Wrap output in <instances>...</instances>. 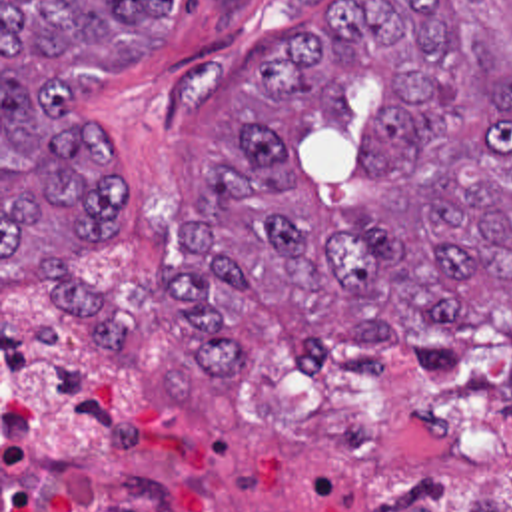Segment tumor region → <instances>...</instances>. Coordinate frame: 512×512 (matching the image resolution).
Masks as SVG:
<instances>
[{
  "label": "tumor region",
  "instance_id": "tumor-region-1",
  "mask_svg": "<svg viewBox=\"0 0 512 512\" xmlns=\"http://www.w3.org/2000/svg\"><path fill=\"white\" fill-rule=\"evenodd\" d=\"M178 13L180 0H2V297L40 289L102 343H130L136 315L80 257L122 213L120 139L84 115L82 79L152 57ZM355 79L385 91L367 133L377 191L347 211L357 229L325 235L274 121L242 117L244 157L208 159L168 275L194 347L168 367L170 397L248 367L226 323L240 295L319 361L379 365L373 351L397 347L437 365L489 309L512 329V0L345 1L246 83L262 103L357 117ZM443 492L435 478L359 512H435L423 498Z\"/></svg>",
  "mask_w": 512,
  "mask_h": 512
}]
</instances>
